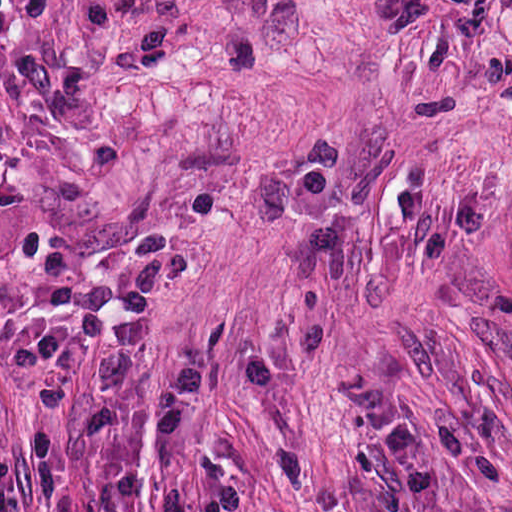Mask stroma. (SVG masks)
<instances>
[{
	"label": "stroma",
	"mask_w": 512,
	"mask_h": 512,
	"mask_svg": "<svg viewBox=\"0 0 512 512\" xmlns=\"http://www.w3.org/2000/svg\"><path fill=\"white\" fill-rule=\"evenodd\" d=\"M0 512H512V91L0 0Z\"/></svg>",
	"instance_id": "stroma-1"
}]
</instances>
